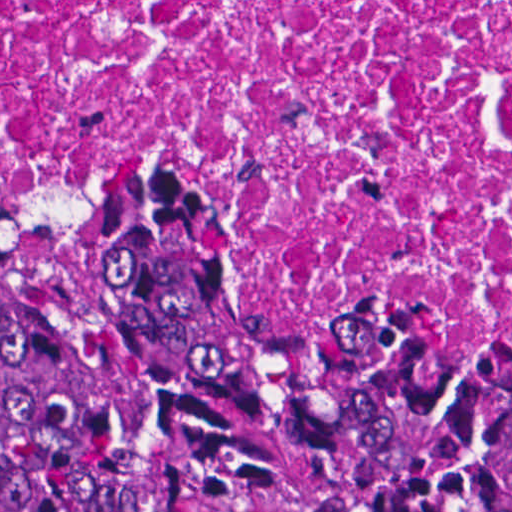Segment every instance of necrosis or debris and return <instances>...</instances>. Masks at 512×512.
<instances>
[{"mask_svg": "<svg viewBox=\"0 0 512 512\" xmlns=\"http://www.w3.org/2000/svg\"><path fill=\"white\" fill-rule=\"evenodd\" d=\"M197 211L512 355V0H1V214Z\"/></svg>", "mask_w": 512, "mask_h": 512, "instance_id": "4bbe7bcc", "label": "necrosis or debris"}]
</instances>
